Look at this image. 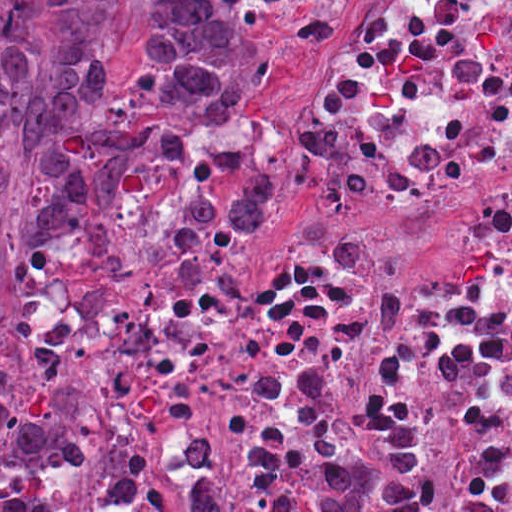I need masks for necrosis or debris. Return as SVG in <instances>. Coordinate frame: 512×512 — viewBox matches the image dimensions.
<instances>
[{
	"mask_svg": "<svg viewBox=\"0 0 512 512\" xmlns=\"http://www.w3.org/2000/svg\"><path fill=\"white\" fill-rule=\"evenodd\" d=\"M313 216L257 262L171 274L102 512L313 497L418 419L430 512H512V0H361L286 151ZM359 452H357V451Z\"/></svg>",
	"mask_w": 512,
	"mask_h": 512,
	"instance_id": "1",
	"label": "necrosis or debris"
}]
</instances>
